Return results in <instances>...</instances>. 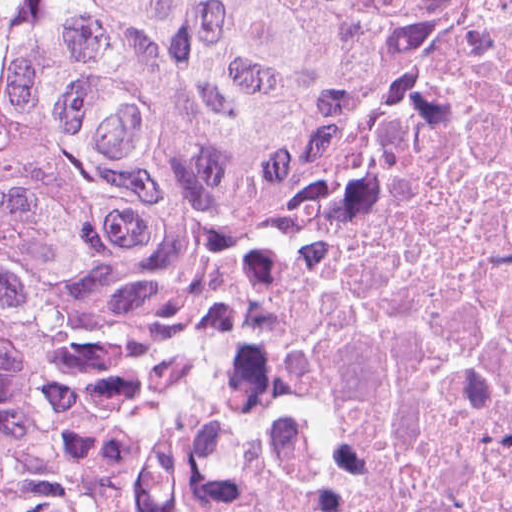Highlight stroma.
I'll return each instance as SVG.
<instances>
[{"mask_svg":"<svg viewBox=\"0 0 512 512\" xmlns=\"http://www.w3.org/2000/svg\"><path fill=\"white\" fill-rule=\"evenodd\" d=\"M32 1L33 0H0V71H1L2 62L7 57V55L10 53V51L12 50V48L16 42L17 36L19 34L21 25H22L24 17H25V14H26L30 4L32 3ZM397 144H396V146H397ZM396 146L394 147V149L396 148ZM394 149L392 150V152L394 151ZM392 152L389 154V156L387 157L385 162L375 173L373 178L378 174V172L381 170V168H383V166L386 164V162L388 161ZM255 386H256V370H255L254 374L252 375L251 379L249 380L245 391L243 392L241 398L235 405L234 409L240 403V401L246 396V394L248 392H250Z\"/></svg>","mask_w":512,"mask_h":512,"instance_id":"obj_1","label":"stroma"}]
</instances>
